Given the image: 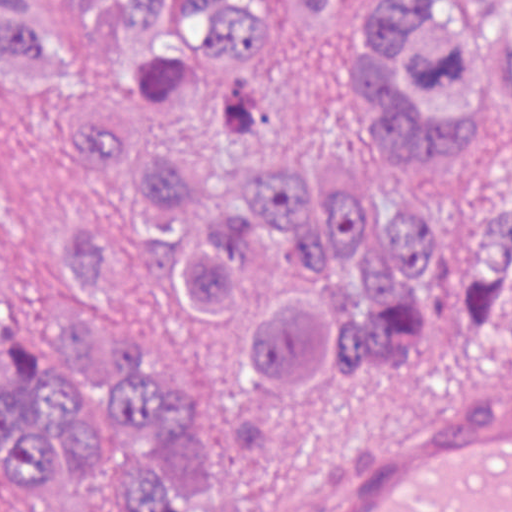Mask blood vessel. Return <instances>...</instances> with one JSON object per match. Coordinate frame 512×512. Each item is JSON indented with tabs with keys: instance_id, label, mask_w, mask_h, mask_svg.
<instances>
[{
	"instance_id": "1",
	"label": "blood vessel",
	"mask_w": 512,
	"mask_h": 512,
	"mask_svg": "<svg viewBox=\"0 0 512 512\" xmlns=\"http://www.w3.org/2000/svg\"><path fill=\"white\" fill-rule=\"evenodd\" d=\"M273 512H512V377L315 467Z\"/></svg>"
}]
</instances>
